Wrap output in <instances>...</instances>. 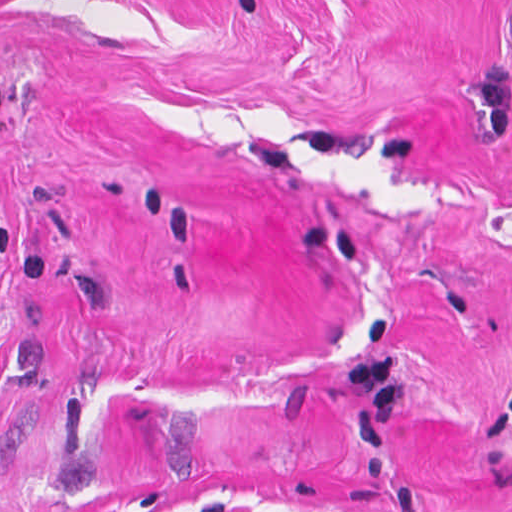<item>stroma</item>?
<instances>
[{
	"label": "stroma",
	"mask_w": 512,
	"mask_h": 512,
	"mask_svg": "<svg viewBox=\"0 0 512 512\" xmlns=\"http://www.w3.org/2000/svg\"><path fill=\"white\" fill-rule=\"evenodd\" d=\"M0 512H512V0H0Z\"/></svg>",
	"instance_id": "stroma-1"
}]
</instances>
